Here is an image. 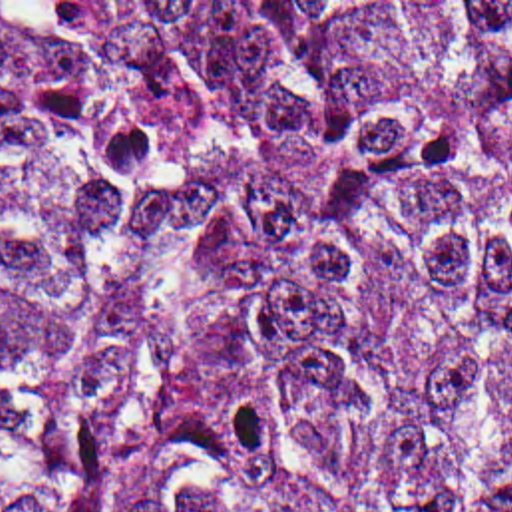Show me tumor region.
<instances>
[{
    "mask_svg": "<svg viewBox=\"0 0 512 512\" xmlns=\"http://www.w3.org/2000/svg\"><path fill=\"white\" fill-rule=\"evenodd\" d=\"M0 512H512V2H0Z\"/></svg>",
    "mask_w": 512,
    "mask_h": 512,
    "instance_id": "obj_1",
    "label": "tumor region"
}]
</instances>
